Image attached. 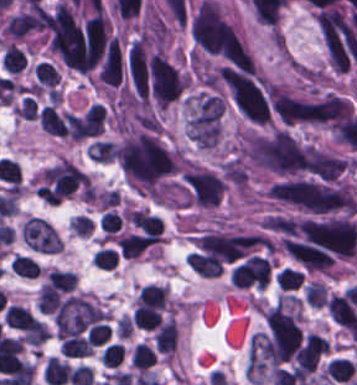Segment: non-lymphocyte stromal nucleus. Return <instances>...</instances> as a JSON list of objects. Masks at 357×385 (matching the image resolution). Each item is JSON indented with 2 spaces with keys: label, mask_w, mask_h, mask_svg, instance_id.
<instances>
[{
  "label": "non-lymphocyte stromal nucleus",
  "mask_w": 357,
  "mask_h": 385,
  "mask_svg": "<svg viewBox=\"0 0 357 385\" xmlns=\"http://www.w3.org/2000/svg\"><path fill=\"white\" fill-rule=\"evenodd\" d=\"M109 310L87 294L73 293L53 313L57 338L65 339L105 322Z\"/></svg>",
  "instance_id": "1"
},
{
  "label": "non-lymphocyte stromal nucleus",
  "mask_w": 357,
  "mask_h": 385,
  "mask_svg": "<svg viewBox=\"0 0 357 385\" xmlns=\"http://www.w3.org/2000/svg\"><path fill=\"white\" fill-rule=\"evenodd\" d=\"M20 237L24 245L36 253L56 254L63 249L54 227L43 217L31 215L22 222Z\"/></svg>",
  "instance_id": "2"
},
{
  "label": "non-lymphocyte stromal nucleus",
  "mask_w": 357,
  "mask_h": 385,
  "mask_svg": "<svg viewBox=\"0 0 357 385\" xmlns=\"http://www.w3.org/2000/svg\"><path fill=\"white\" fill-rule=\"evenodd\" d=\"M74 236L88 237L93 231V224L90 219L82 215H74L68 225Z\"/></svg>",
  "instance_id": "3"
}]
</instances>
